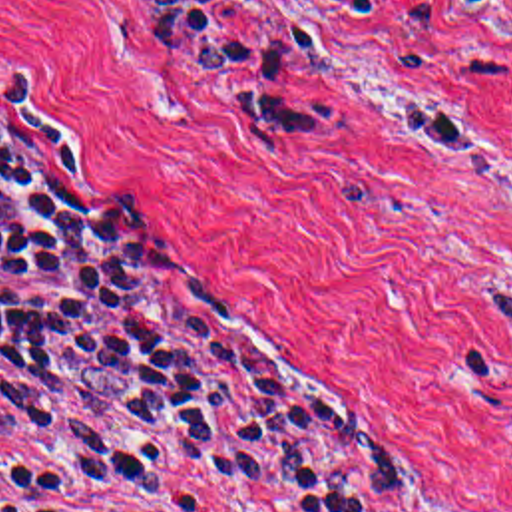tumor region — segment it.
Returning <instances> with one entry per match:
<instances>
[{
  "label": "tumor region",
  "mask_w": 512,
  "mask_h": 512,
  "mask_svg": "<svg viewBox=\"0 0 512 512\" xmlns=\"http://www.w3.org/2000/svg\"><path fill=\"white\" fill-rule=\"evenodd\" d=\"M489 320L512 336V278L489 288Z\"/></svg>",
  "instance_id": "e687c5a6"
}]
</instances>
